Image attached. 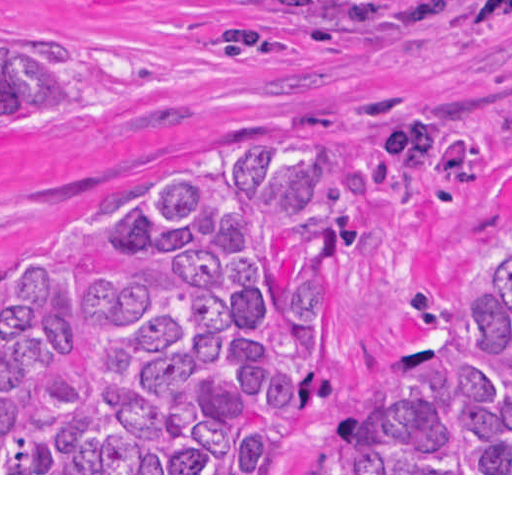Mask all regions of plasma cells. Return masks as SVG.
Listing matches in <instances>:
<instances>
[{"mask_svg": "<svg viewBox=\"0 0 512 512\" xmlns=\"http://www.w3.org/2000/svg\"><path fill=\"white\" fill-rule=\"evenodd\" d=\"M470 6H475L494 14L512 12V0H471Z\"/></svg>", "mask_w": 512, "mask_h": 512, "instance_id": "9512152a", "label": "plasma cells"}]
</instances>
